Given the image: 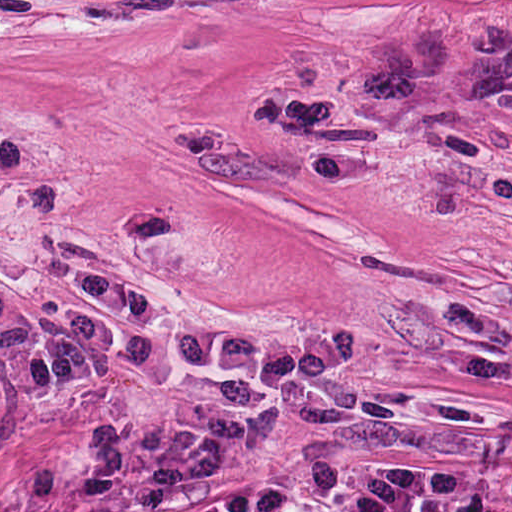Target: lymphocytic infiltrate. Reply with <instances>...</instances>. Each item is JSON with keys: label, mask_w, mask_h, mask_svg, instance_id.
<instances>
[{"label": "lymphocytic infiltrate", "mask_w": 512, "mask_h": 512, "mask_svg": "<svg viewBox=\"0 0 512 512\" xmlns=\"http://www.w3.org/2000/svg\"><path fill=\"white\" fill-rule=\"evenodd\" d=\"M376 70L469 86L512 105V17H478L371 65Z\"/></svg>", "instance_id": "obj_1"}]
</instances>
